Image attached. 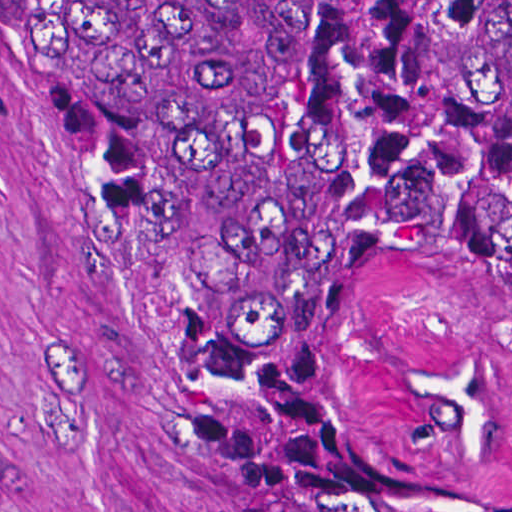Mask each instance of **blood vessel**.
I'll use <instances>...</instances> for the list:
<instances>
[{
  "instance_id": "8fb6f2fc",
  "label": "blood vessel",
  "mask_w": 512,
  "mask_h": 512,
  "mask_svg": "<svg viewBox=\"0 0 512 512\" xmlns=\"http://www.w3.org/2000/svg\"><path fill=\"white\" fill-rule=\"evenodd\" d=\"M346 400L383 451L437 480L512 473V301L474 272L411 266L366 305Z\"/></svg>"
}]
</instances>
